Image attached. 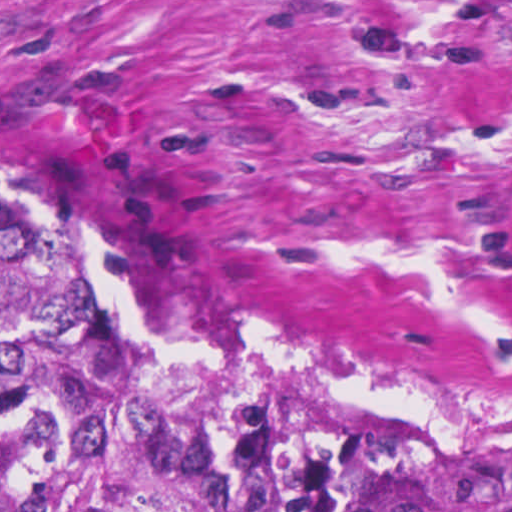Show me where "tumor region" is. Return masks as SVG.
<instances>
[{
  "instance_id": "tumor-region-1",
  "label": "tumor region",
  "mask_w": 512,
  "mask_h": 512,
  "mask_svg": "<svg viewBox=\"0 0 512 512\" xmlns=\"http://www.w3.org/2000/svg\"><path fill=\"white\" fill-rule=\"evenodd\" d=\"M91 250L0 166V512H512V428L141 331Z\"/></svg>"
}]
</instances>
